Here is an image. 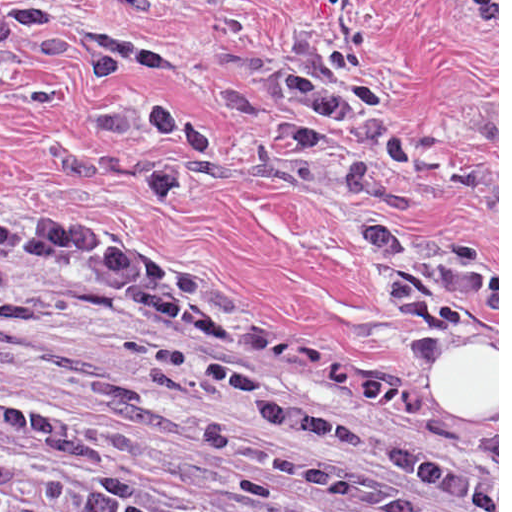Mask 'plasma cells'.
Returning a JSON list of instances; mask_svg holds the SVG:
<instances>
[{"mask_svg":"<svg viewBox=\"0 0 512 512\" xmlns=\"http://www.w3.org/2000/svg\"><path fill=\"white\" fill-rule=\"evenodd\" d=\"M100 10H153L176 0H73ZM171 46L136 33L89 31L81 63L100 95L87 119L98 138L162 140L144 159L154 205L184 194L177 159L215 149L201 120L157 96L133 100L130 77L157 79L178 67ZM284 119L266 147L313 162L352 200L368 197L373 175L342 148L377 157L390 203L357 231L359 243L394 295L408 349L427 362L472 322L492 278L478 249L419 240L407 222L427 170L461 200L490 206L498 182L398 119L369 72L359 42L341 38L292 64L276 87ZM57 274L90 287L114 311L136 368L201 379L220 395L252 400L258 430L206 427L204 444L272 482L300 490V502L209 498L161 507L143 483L24 469L0 460V512H498V433L436 429L426 417L323 364L280 326L245 323L164 293L147 261L92 248L0 235V291L21 275Z\"/></svg>","mask_w":512,"mask_h":512,"instance_id":"9512152a","label":"plasma cells"}]
</instances>
